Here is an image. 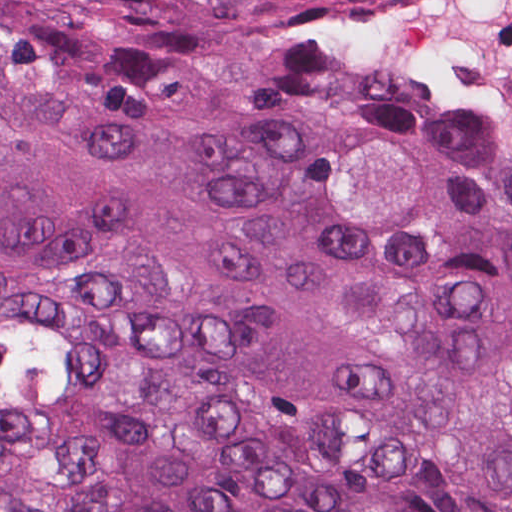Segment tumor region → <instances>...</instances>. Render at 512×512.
<instances>
[{"label": "tumor region", "mask_w": 512, "mask_h": 512, "mask_svg": "<svg viewBox=\"0 0 512 512\" xmlns=\"http://www.w3.org/2000/svg\"><path fill=\"white\" fill-rule=\"evenodd\" d=\"M345 1L0 0V512H512V155Z\"/></svg>", "instance_id": "obj_1"}]
</instances>
